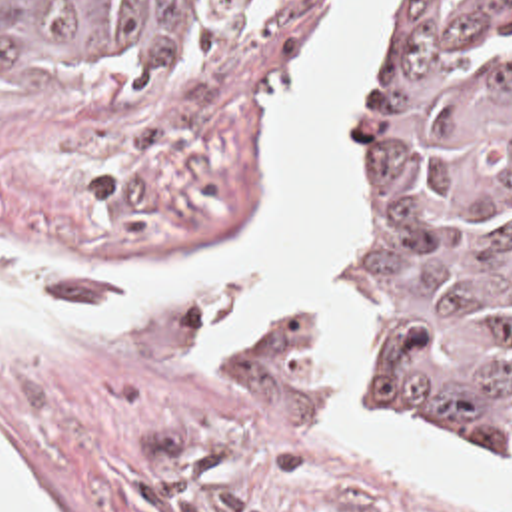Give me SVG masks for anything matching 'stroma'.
<instances>
[{
	"mask_svg": "<svg viewBox=\"0 0 512 512\" xmlns=\"http://www.w3.org/2000/svg\"><path fill=\"white\" fill-rule=\"evenodd\" d=\"M339 1L267 0L233 49L157 83H47L0 37V285L115 319L101 332H0L1 452L57 512H512L331 440L335 378L311 309L277 311L213 350L203 336L243 283L147 305L125 291V267L259 225V149L275 97ZM403 1L385 7L349 117L343 285L367 342V398L385 416L389 380L369 315L365 117ZM393 426L512 468L511 444Z\"/></svg>",
	"mask_w": 512,
	"mask_h": 512,
	"instance_id": "35a3bbf8",
	"label": "stroma"
}]
</instances>
